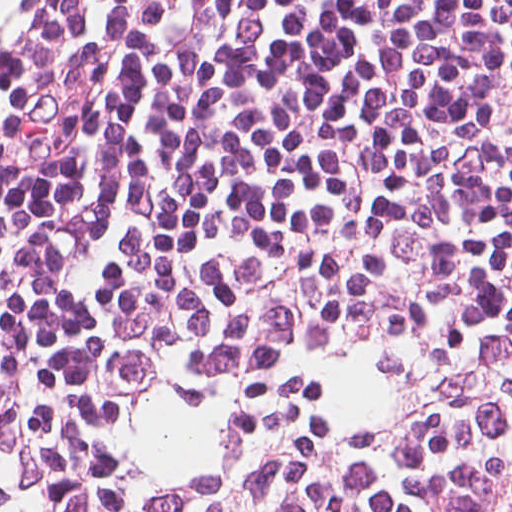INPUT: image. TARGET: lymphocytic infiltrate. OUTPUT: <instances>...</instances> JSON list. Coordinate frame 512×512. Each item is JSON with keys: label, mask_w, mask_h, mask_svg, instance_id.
<instances>
[{"label": "lymphocytic infiltrate", "mask_w": 512, "mask_h": 512, "mask_svg": "<svg viewBox=\"0 0 512 512\" xmlns=\"http://www.w3.org/2000/svg\"><path fill=\"white\" fill-rule=\"evenodd\" d=\"M0 512H512V0H59Z\"/></svg>", "instance_id": "f902f5d3"}]
</instances>
